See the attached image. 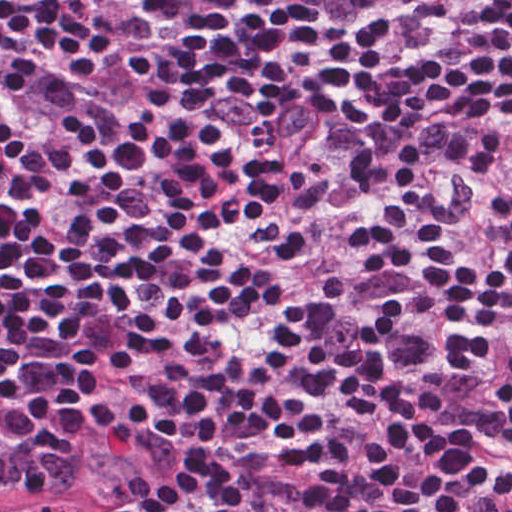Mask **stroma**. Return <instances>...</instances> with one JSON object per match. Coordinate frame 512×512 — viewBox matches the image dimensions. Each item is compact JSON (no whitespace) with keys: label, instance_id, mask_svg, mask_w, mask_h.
<instances>
[{"label":"stroma","instance_id":"obj_1","mask_svg":"<svg viewBox=\"0 0 512 512\" xmlns=\"http://www.w3.org/2000/svg\"><path fill=\"white\" fill-rule=\"evenodd\" d=\"M125 512H143L111 484L97 478H69L0 488V507L21 512H99L110 501Z\"/></svg>","mask_w":512,"mask_h":512}]
</instances>
